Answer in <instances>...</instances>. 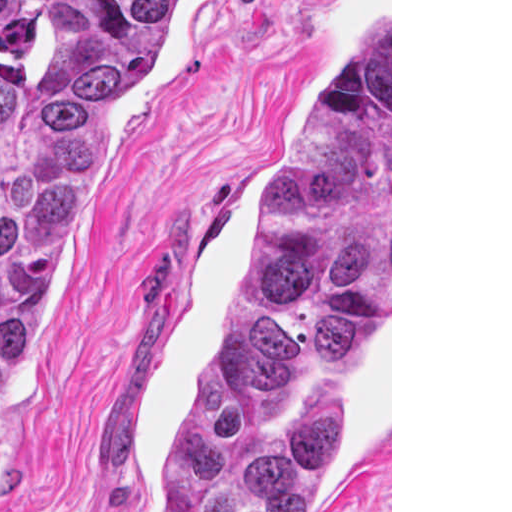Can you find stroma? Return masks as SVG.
<instances>
[{
  "mask_svg": "<svg viewBox=\"0 0 512 512\" xmlns=\"http://www.w3.org/2000/svg\"><path fill=\"white\" fill-rule=\"evenodd\" d=\"M390 26V308L306 512H392V0H204L108 111L39 283L0 512H153L199 367L261 274L270 184Z\"/></svg>",
  "mask_w": 512,
  "mask_h": 512,
  "instance_id": "obj_1",
  "label": "stroma"
}]
</instances>
